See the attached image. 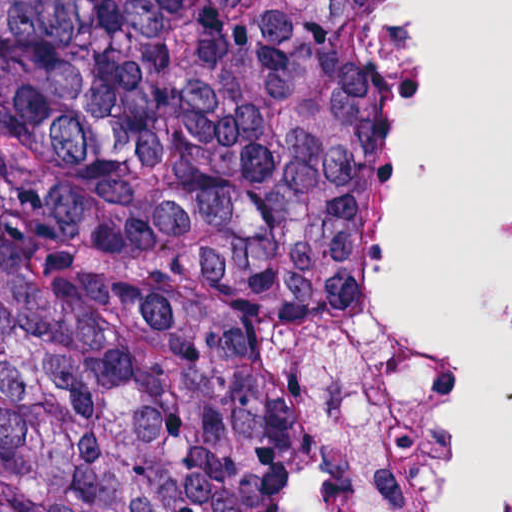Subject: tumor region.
<instances>
[{
  "label": "tumor region",
  "mask_w": 512,
  "mask_h": 512,
  "mask_svg": "<svg viewBox=\"0 0 512 512\" xmlns=\"http://www.w3.org/2000/svg\"><path fill=\"white\" fill-rule=\"evenodd\" d=\"M392 196L386 0H0V512H242Z\"/></svg>",
  "instance_id": "tumor-region-1"
}]
</instances>
